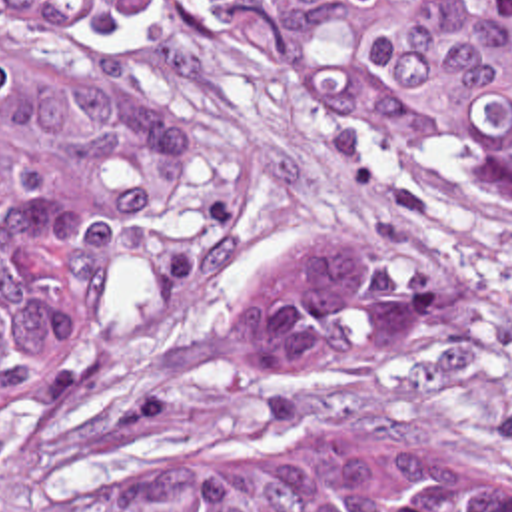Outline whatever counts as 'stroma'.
<instances>
[{
    "mask_svg": "<svg viewBox=\"0 0 512 512\" xmlns=\"http://www.w3.org/2000/svg\"><path fill=\"white\" fill-rule=\"evenodd\" d=\"M117 37L161 109L163 177L125 235L81 370L145 378L239 283L299 259L426 251L448 279L442 331L287 398L203 396L207 410L263 436H454L512 450V217L171 1H133ZM61 51L57 19L0 11V63ZM147 462L141 428L97 424L63 384L45 424L0 440V512L105 494Z\"/></svg>",
    "mask_w": 512,
    "mask_h": 512,
    "instance_id": "1",
    "label": "stroma"
}]
</instances>
